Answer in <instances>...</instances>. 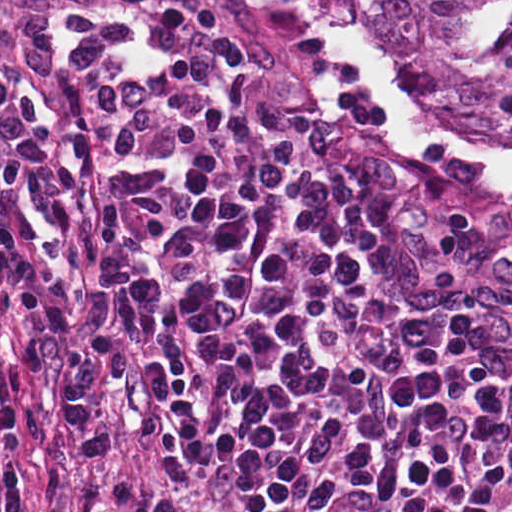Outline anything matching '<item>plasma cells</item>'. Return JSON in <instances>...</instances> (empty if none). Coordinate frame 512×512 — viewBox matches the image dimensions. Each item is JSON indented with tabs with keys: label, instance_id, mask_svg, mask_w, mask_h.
I'll list each match as a JSON object with an SVG mask.
<instances>
[{
	"label": "plasma cells",
	"instance_id": "1",
	"mask_svg": "<svg viewBox=\"0 0 512 512\" xmlns=\"http://www.w3.org/2000/svg\"><path fill=\"white\" fill-rule=\"evenodd\" d=\"M0 259L225 512H512L497 323L254 146L204 0H0Z\"/></svg>",
	"mask_w": 512,
	"mask_h": 512
}]
</instances>
